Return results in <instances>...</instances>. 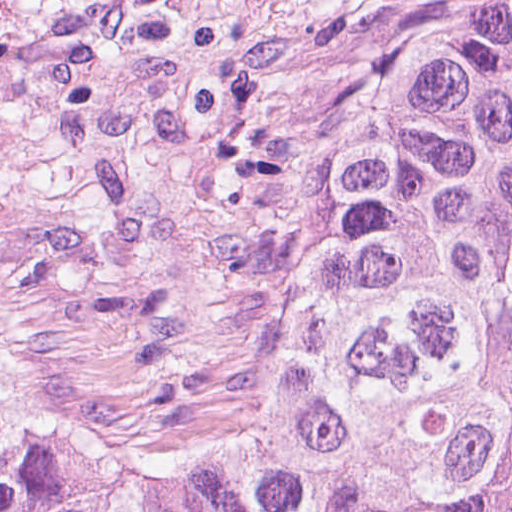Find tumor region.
I'll return each instance as SVG.
<instances>
[{
  "mask_svg": "<svg viewBox=\"0 0 512 512\" xmlns=\"http://www.w3.org/2000/svg\"><path fill=\"white\" fill-rule=\"evenodd\" d=\"M0 0V512H512V0L416 28L355 91L282 349L193 433L29 364Z\"/></svg>",
  "mask_w": 512,
  "mask_h": 512,
  "instance_id": "1",
  "label": "tumor region"
}]
</instances>
